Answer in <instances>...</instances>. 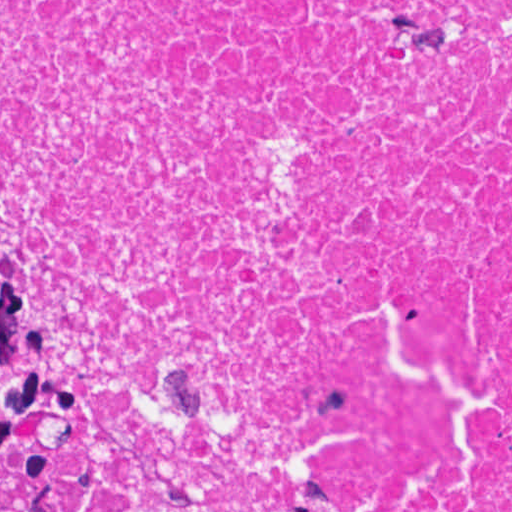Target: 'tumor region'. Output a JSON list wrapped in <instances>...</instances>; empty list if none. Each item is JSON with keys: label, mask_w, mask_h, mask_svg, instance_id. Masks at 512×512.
Wrapping results in <instances>:
<instances>
[{"label": "tumor region", "mask_w": 512, "mask_h": 512, "mask_svg": "<svg viewBox=\"0 0 512 512\" xmlns=\"http://www.w3.org/2000/svg\"><path fill=\"white\" fill-rule=\"evenodd\" d=\"M0 512H75L72 479L0 321Z\"/></svg>", "instance_id": "tumor-region-1"}]
</instances>
